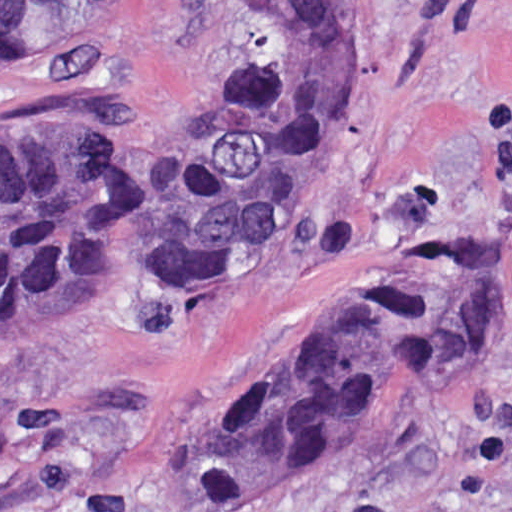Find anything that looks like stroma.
<instances>
[{
  "instance_id": "obj_1",
  "label": "stroma",
  "mask_w": 512,
  "mask_h": 512,
  "mask_svg": "<svg viewBox=\"0 0 512 512\" xmlns=\"http://www.w3.org/2000/svg\"><path fill=\"white\" fill-rule=\"evenodd\" d=\"M251 1H379L355 28L341 158L220 292L0 336V512H195L186 460L216 402L383 268L444 233L512 280V0H130L0 57V135L186 140L250 51ZM269 512H512V329Z\"/></svg>"
}]
</instances>
